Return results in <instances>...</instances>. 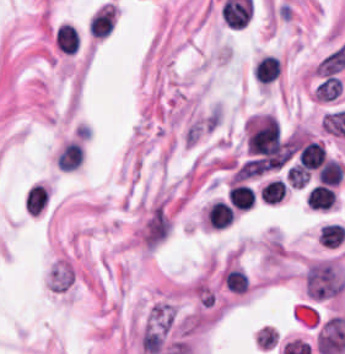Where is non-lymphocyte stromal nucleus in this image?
Masks as SVG:
<instances>
[{"instance_id":"1","label":"non-lymphocyte stromal nucleus","mask_w":345,"mask_h":354,"mask_svg":"<svg viewBox=\"0 0 345 354\" xmlns=\"http://www.w3.org/2000/svg\"><path fill=\"white\" fill-rule=\"evenodd\" d=\"M77 281V269L71 258L60 256L49 265L46 286L54 295H66Z\"/></svg>"}]
</instances>
